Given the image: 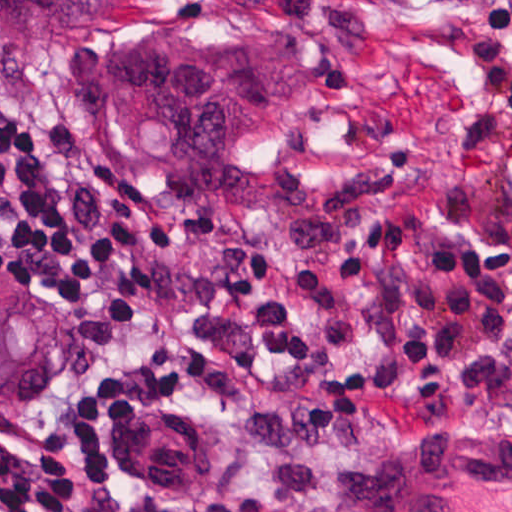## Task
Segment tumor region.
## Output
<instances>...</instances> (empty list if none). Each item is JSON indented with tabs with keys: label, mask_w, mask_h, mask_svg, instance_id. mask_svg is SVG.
Masks as SVG:
<instances>
[{
	"label": "tumor region",
	"mask_w": 512,
	"mask_h": 512,
	"mask_svg": "<svg viewBox=\"0 0 512 512\" xmlns=\"http://www.w3.org/2000/svg\"><path fill=\"white\" fill-rule=\"evenodd\" d=\"M90 39L80 93L116 170L153 201L316 209L328 191L271 161L311 115L310 59L236 18L116 21L104 0H0V52ZM66 370L58 310L0 274V410L49 395Z\"/></svg>",
	"instance_id": "tumor-region-1"
}]
</instances>
